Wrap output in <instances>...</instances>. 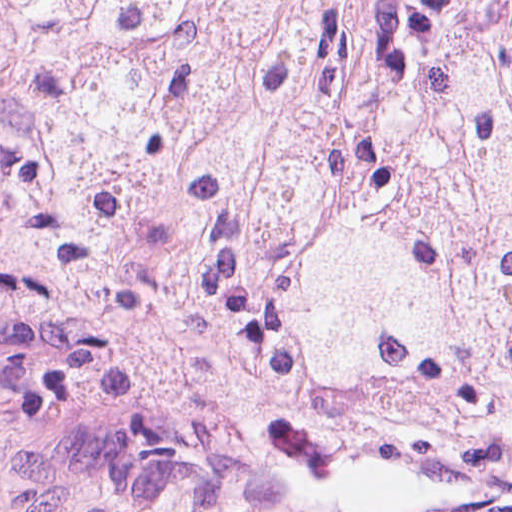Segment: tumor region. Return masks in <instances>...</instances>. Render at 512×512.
<instances>
[{"label":"tumor region","instance_id":"e687c5a6","mask_svg":"<svg viewBox=\"0 0 512 512\" xmlns=\"http://www.w3.org/2000/svg\"><path fill=\"white\" fill-rule=\"evenodd\" d=\"M0 321L512 421V0H0Z\"/></svg>","mask_w":512,"mask_h":512}]
</instances>
